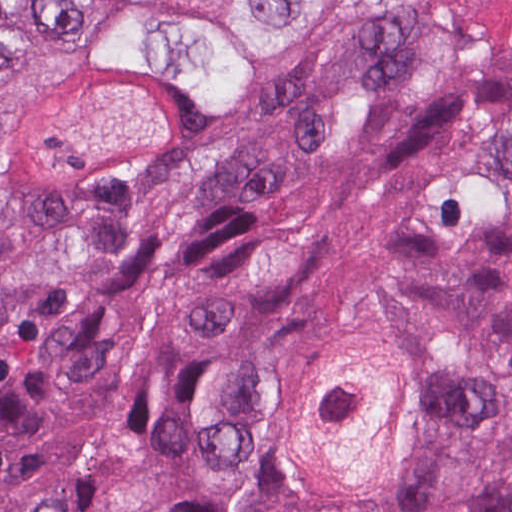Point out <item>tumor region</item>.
<instances>
[{
	"label": "tumor region",
	"mask_w": 512,
	"mask_h": 512,
	"mask_svg": "<svg viewBox=\"0 0 512 512\" xmlns=\"http://www.w3.org/2000/svg\"><path fill=\"white\" fill-rule=\"evenodd\" d=\"M0 512H512V0H0Z\"/></svg>",
	"instance_id": "e687c5a6"
}]
</instances>
